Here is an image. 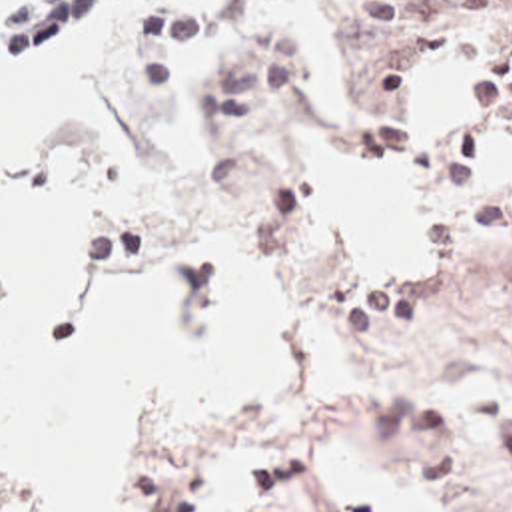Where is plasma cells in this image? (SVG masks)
Masks as SVG:
<instances>
[{
	"mask_svg": "<svg viewBox=\"0 0 512 512\" xmlns=\"http://www.w3.org/2000/svg\"><path fill=\"white\" fill-rule=\"evenodd\" d=\"M459 2L465 14L427 18L411 37L445 61L457 105L489 109L512 123V0ZM383 417L429 487L435 512H512V501H483L467 485L449 423L431 403L395 405Z\"/></svg>",
	"mask_w": 512,
	"mask_h": 512,
	"instance_id": "9512152a",
	"label": "plasma cells"
}]
</instances>
